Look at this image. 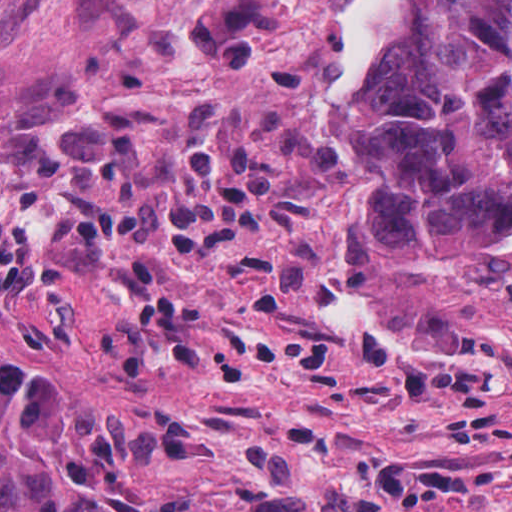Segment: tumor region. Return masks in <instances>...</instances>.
Listing matches in <instances>:
<instances>
[{"instance_id": "e687c5a6", "label": "tumor region", "mask_w": 512, "mask_h": 512, "mask_svg": "<svg viewBox=\"0 0 512 512\" xmlns=\"http://www.w3.org/2000/svg\"><path fill=\"white\" fill-rule=\"evenodd\" d=\"M331 105L372 128L347 264L461 269L512 240V0H397Z\"/></svg>"}]
</instances>
